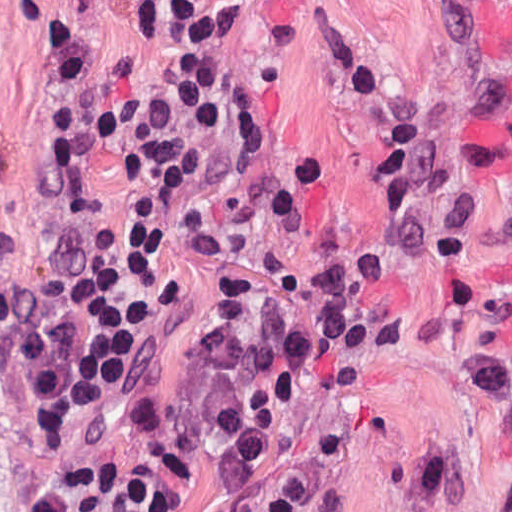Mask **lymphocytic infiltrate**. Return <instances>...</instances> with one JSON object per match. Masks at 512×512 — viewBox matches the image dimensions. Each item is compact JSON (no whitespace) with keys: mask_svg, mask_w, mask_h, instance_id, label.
Instances as JSON below:
<instances>
[{"mask_svg":"<svg viewBox=\"0 0 512 512\" xmlns=\"http://www.w3.org/2000/svg\"><path fill=\"white\" fill-rule=\"evenodd\" d=\"M168 1H47L72 59L66 131L93 250L36 327L13 379L16 413L47 422L98 385L152 285L166 225L215 110L209 59L178 53ZM304 260L225 246L206 261L202 303L170 346L137 425L154 475L203 509L240 498L307 424L353 349L299 289ZM29 512H139L126 457L93 449Z\"/></svg>","mask_w":512,"mask_h":512,"instance_id":"f902f5d3","label":"lymphocytic infiltrate"}]
</instances>
